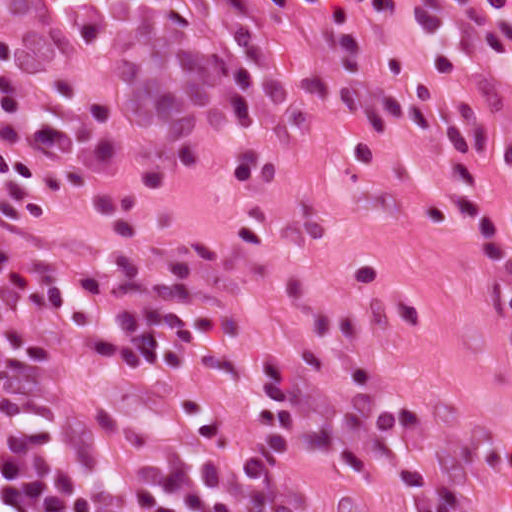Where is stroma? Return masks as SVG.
I'll return each instance as SVG.
<instances>
[{"mask_svg":"<svg viewBox=\"0 0 512 512\" xmlns=\"http://www.w3.org/2000/svg\"><path fill=\"white\" fill-rule=\"evenodd\" d=\"M504 90L489 135L512 122V0ZM0 36L18 41L14 86L30 112H70L55 82L95 95L114 121L119 191L149 169L166 176L141 214L142 235L115 238L81 197L57 193L55 220L0 218V262L29 274L95 264L152 271L197 288L216 309L221 348L190 372L132 369L77 377L83 417L198 422L248 436L262 366L306 349L349 353L400 401L373 455L312 450L294 464L296 512H408L436 497L453 512H512V313L505 279L457 200L451 147L428 149L398 127L314 112L213 125L198 146L141 130L112 77L88 68L66 0H0ZM19 154L51 158L5 135ZM510 232L512 172L485 166Z\"/></svg>","mask_w":512,"mask_h":512,"instance_id":"35a3bbf8","label":"stroma"}]
</instances>
